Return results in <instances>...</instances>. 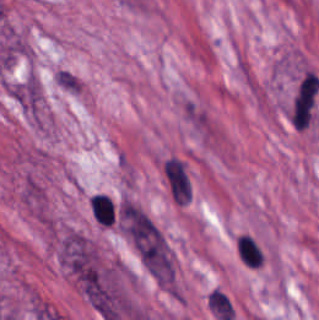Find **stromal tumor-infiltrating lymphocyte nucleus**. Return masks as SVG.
Listing matches in <instances>:
<instances>
[{
  "mask_svg": "<svg viewBox=\"0 0 319 320\" xmlns=\"http://www.w3.org/2000/svg\"><path fill=\"white\" fill-rule=\"evenodd\" d=\"M89 214L97 225L110 227L113 223V210L109 198L95 194L88 200Z\"/></svg>",
  "mask_w": 319,
  "mask_h": 320,
  "instance_id": "1",
  "label": "stromal tumor-infiltrating lymphocyte nucleus"
},
{
  "mask_svg": "<svg viewBox=\"0 0 319 320\" xmlns=\"http://www.w3.org/2000/svg\"><path fill=\"white\" fill-rule=\"evenodd\" d=\"M238 255L247 267H256L262 263L260 250L250 236L238 235L236 238Z\"/></svg>",
  "mask_w": 319,
  "mask_h": 320,
  "instance_id": "2",
  "label": "stromal tumor-infiltrating lymphocyte nucleus"
}]
</instances>
